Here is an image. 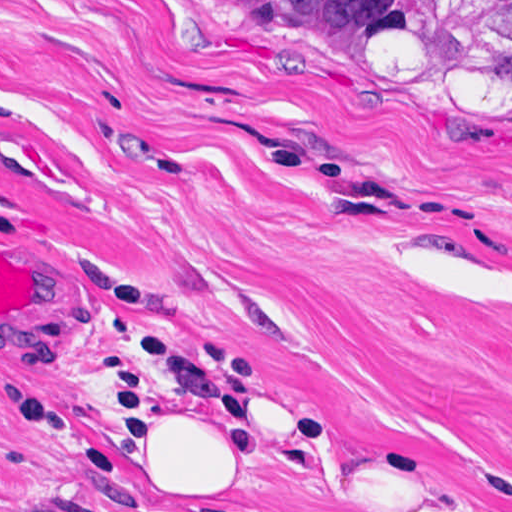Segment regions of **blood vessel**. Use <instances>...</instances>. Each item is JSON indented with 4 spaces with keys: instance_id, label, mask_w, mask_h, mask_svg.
Segmentation results:
<instances>
[{
    "instance_id": "obj_1",
    "label": "blood vessel",
    "mask_w": 512,
    "mask_h": 512,
    "mask_svg": "<svg viewBox=\"0 0 512 512\" xmlns=\"http://www.w3.org/2000/svg\"><path fill=\"white\" fill-rule=\"evenodd\" d=\"M0 317L33 322L38 329L54 317V291L15 255L0 250Z\"/></svg>"
}]
</instances>
